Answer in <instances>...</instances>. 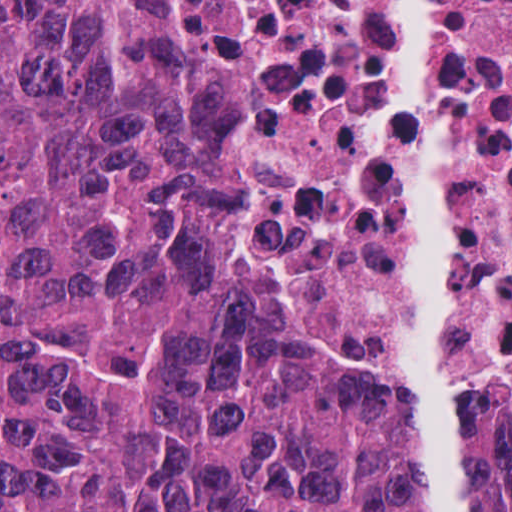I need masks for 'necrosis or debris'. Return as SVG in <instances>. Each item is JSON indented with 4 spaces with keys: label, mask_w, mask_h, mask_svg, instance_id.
Masks as SVG:
<instances>
[{
    "label": "necrosis or debris",
    "mask_w": 512,
    "mask_h": 512,
    "mask_svg": "<svg viewBox=\"0 0 512 512\" xmlns=\"http://www.w3.org/2000/svg\"><path fill=\"white\" fill-rule=\"evenodd\" d=\"M219 260L310 402L512 420V0H178Z\"/></svg>",
    "instance_id": "1"
}]
</instances>
